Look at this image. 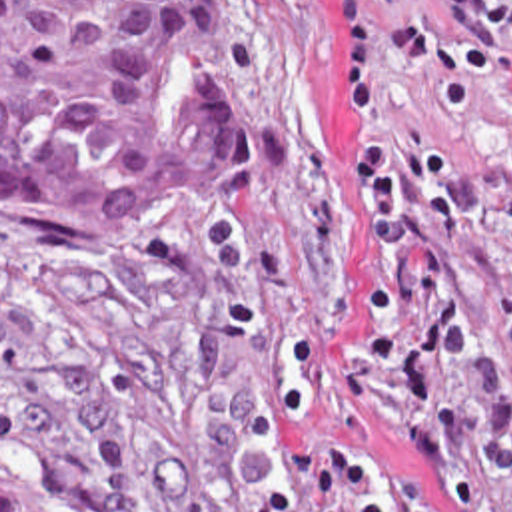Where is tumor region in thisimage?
Returning <instances> with one entry per match:
<instances>
[{"label": "tumor region", "instance_id": "1", "mask_svg": "<svg viewBox=\"0 0 512 512\" xmlns=\"http://www.w3.org/2000/svg\"><path fill=\"white\" fill-rule=\"evenodd\" d=\"M262 167L244 0H0V217L164 251ZM0 512H70L0 452Z\"/></svg>", "mask_w": 512, "mask_h": 512}]
</instances>
